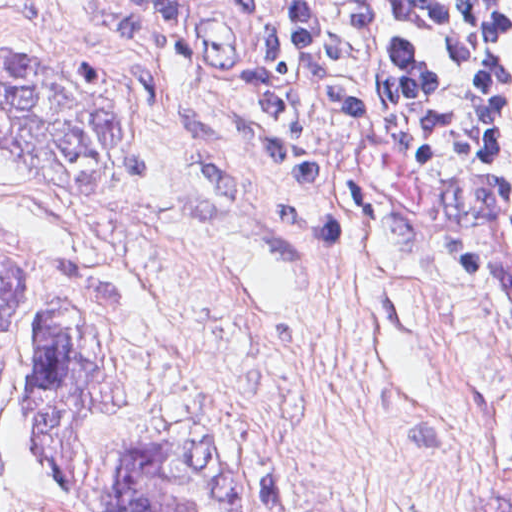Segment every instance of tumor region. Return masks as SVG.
Wrapping results in <instances>:
<instances>
[{"mask_svg": "<svg viewBox=\"0 0 512 512\" xmlns=\"http://www.w3.org/2000/svg\"><path fill=\"white\" fill-rule=\"evenodd\" d=\"M0 147L69 196L144 180V130L123 75L92 59L0 51ZM138 285L113 257L0 241V495L26 409L47 425V470L70 512H259V463L219 421L162 424L99 461L68 444L70 423L130 406L116 332Z\"/></svg>", "mask_w": 512, "mask_h": 512, "instance_id": "obj_1", "label": "tumor region"}]
</instances>
